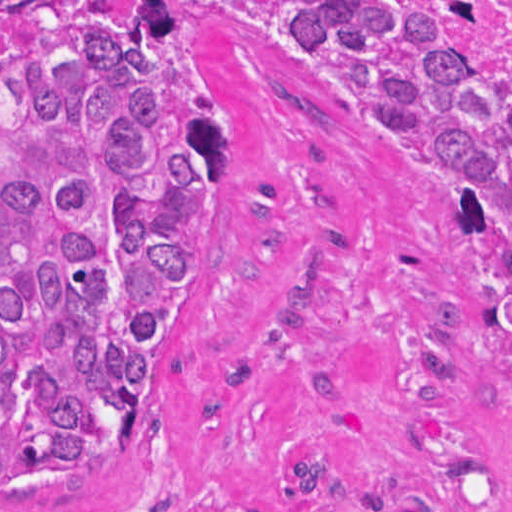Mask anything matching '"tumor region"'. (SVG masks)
Instances as JSON below:
<instances>
[{
    "instance_id": "e687c5a6",
    "label": "tumor region",
    "mask_w": 512,
    "mask_h": 512,
    "mask_svg": "<svg viewBox=\"0 0 512 512\" xmlns=\"http://www.w3.org/2000/svg\"><path fill=\"white\" fill-rule=\"evenodd\" d=\"M265 28L449 191L512 380V62L469 54L431 1H278ZM223 127L186 1H0V507L128 453L201 263Z\"/></svg>"
}]
</instances>
